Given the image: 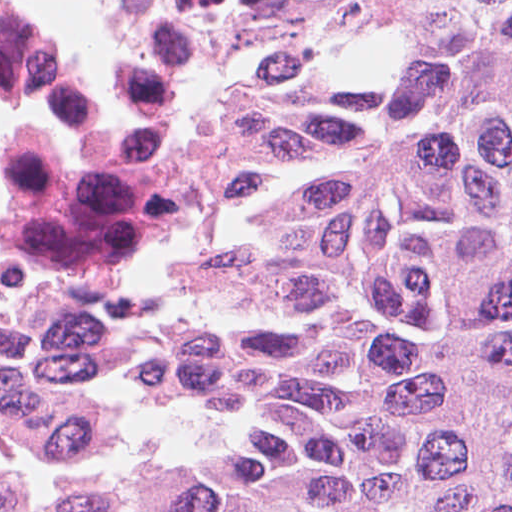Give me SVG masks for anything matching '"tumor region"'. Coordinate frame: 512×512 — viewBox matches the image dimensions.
I'll list each match as a JSON object with an SVG mask.
<instances>
[{
    "instance_id": "obj_1",
    "label": "tumor region",
    "mask_w": 512,
    "mask_h": 512,
    "mask_svg": "<svg viewBox=\"0 0 512 512\" xmlns=\"http://www.w3.org/2000/svg\"><path fill=\"white\" fill-rule=\"evenodd\" d=\"M165 2L173 56L377 43L384 77L242 86L234 216L79 339L71 440L114 444L134 385L228 450L0 512H512V0ZM183 186L173 98L158 245Z\"/></svg>"
}]
</instances>
